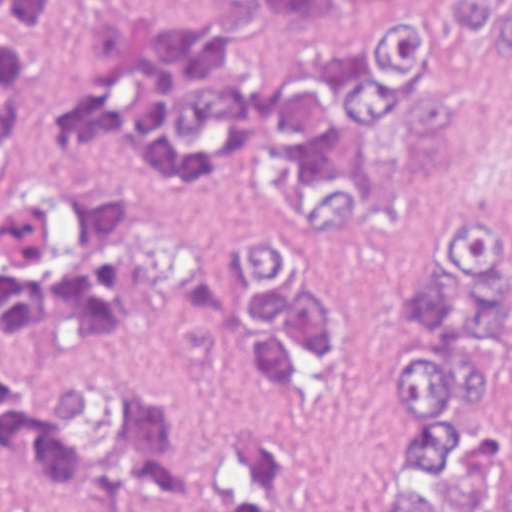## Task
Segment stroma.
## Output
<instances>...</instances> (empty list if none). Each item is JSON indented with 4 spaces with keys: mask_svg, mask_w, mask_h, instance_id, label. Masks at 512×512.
Returning <instances> with one entry per match:
<instances>
[{
    "mask_svg": "<svg viewBox=\"0 0 512 512\" xmlns=\"http://www.w3.org/2000/svg\"><path fill=\"white\" fill-rule=\"evenodd\" d=\"M507 9L512 0H499ZM246 0H98L75 43L26 67V121L55 131L61 103L93 91L100 76L91 24L151 8L158 24L201 25ZM457 0H331L254 19L247 34L195 49L189 74L268 81L307 47L362 44L382 21L446 22ZM452 90L455 149L447 165L418 167L398 94L349 133L321 181L350 186L337 218L280 235L299 296L331 307V345L319 354L280 334L286 347L281 393L246 360L254 325L246 317L250 271L240 260L254 232L309 223L313 196L298 168L273 148L268 121L222 133L202 158L170 154L151 109L158 163L189 170L196 197L182 218L183 281L174 297L134 303L107 336H74L52 325L0 331V368L21 377L99 358L145 369L176 401L179 452L165 486L141 497L53 493L33 485L0 451L5 512H188L215 458L254 441L276 445L284 465L279 512H375L379 459L396 442L391 401L403 364L392 329L404 286L423 275V233L436 214L512 209V79L509 60L475 26L448 29L425 69ZM38 178L29 144L7 140L0 157V215Z\"/></svg>",
    "mask_w": 512,
    "mask_h": 512,
    "instance_id": "35a3bbf8",
    "label": "stroma"
}]
</instances>
